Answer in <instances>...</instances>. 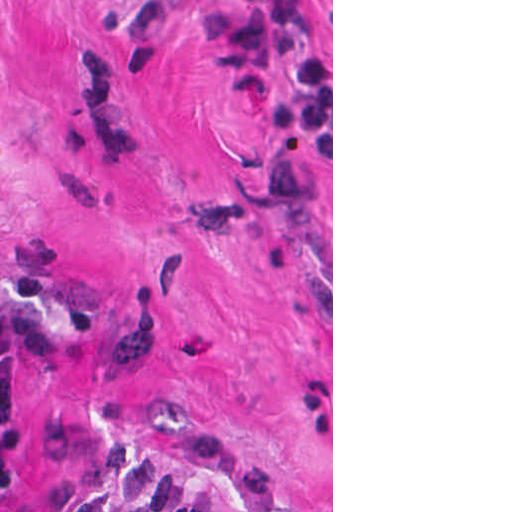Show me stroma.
Instances as JSON below:
<instances>
[{
	"label": "stroma",
	"mask_w": 512,
	"mask_h": 512,
	"mask_svg": "<svg viewBox=\"0 0 512 512\" xmlns=\"http://www.w3.org/2000/svg\"><path fill=\"white\" fill-rule=\"evenodd\" d=\"M0 291L71 333L9 507L137 446L333 512V0H0Z\"/></svg>",
	"instance_id": "1"
}]
</instances>
